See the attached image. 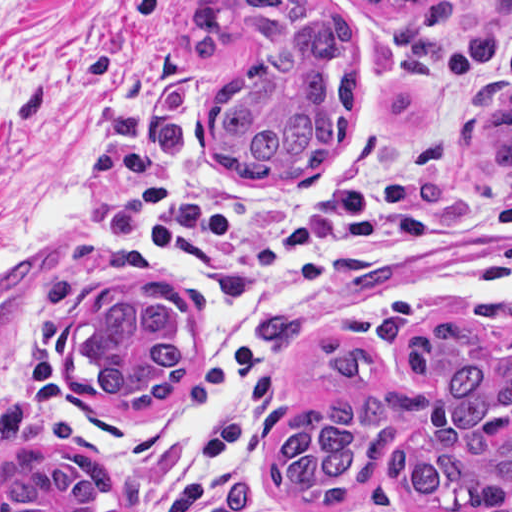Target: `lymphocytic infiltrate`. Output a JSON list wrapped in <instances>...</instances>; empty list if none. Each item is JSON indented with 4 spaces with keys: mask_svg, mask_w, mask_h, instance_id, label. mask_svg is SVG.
<instances>
[{
    "mask_svg": "<svg viewBox=\"0 0 512 512\" xmlns=\"http://www.w3.org/2000/svg\"><path fill=\"white\" fill-rule=\"evenodd\" d=\"M497 79L512 83V32L456 111L383 148L344 145L295 192L194 184L146 202L139 236L192 280L221 338L180 413L168 479L130 512H296L266 449L283 375L310 334L512 302V194L444 181L448 130Z\"/></svg>",
    "mask_w": 512,
    "mask_h": 512,
    "instance_id": "1",
    "label": "lymphocytic infiltrate"
}]
</instances>
